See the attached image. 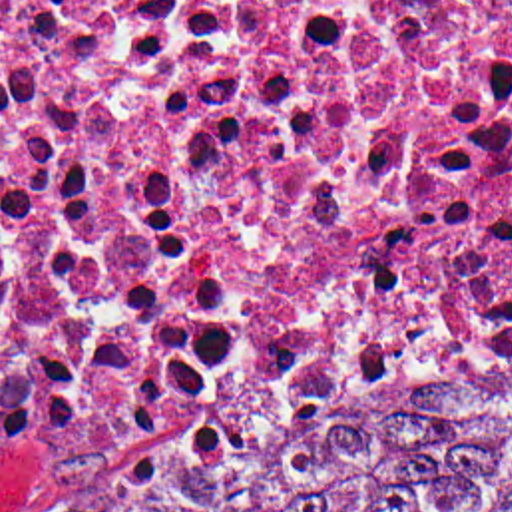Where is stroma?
I'll return each mask as SVG.
<instances>
[{
    "mask_svg": "<svg viewBox=\"0 0 512 512\" xmlns=\"http://www.w3.org/2000/svg\"><path fill=\"white\" fill-rule=\"evenodd\" d=\"M253 444V442H251ZM251 444H243V446H239V448H233V450H229V452H223V454H219V456H215V458H211V460H207V464L203 466V468H207V466H211V464H215V462H219V460H223V458H227V456H231V454H235V452H239V450H243V448H247V446H251ZM6 512H40L38 508L30 502V500H26L22 494L12 502V506L6 509Z\"/></svg>",
    "mask_w": 512,
    "mask_h": 512,
    "instance_id": "stroma-1",
    "label": "stroma"
}]
</instances>
